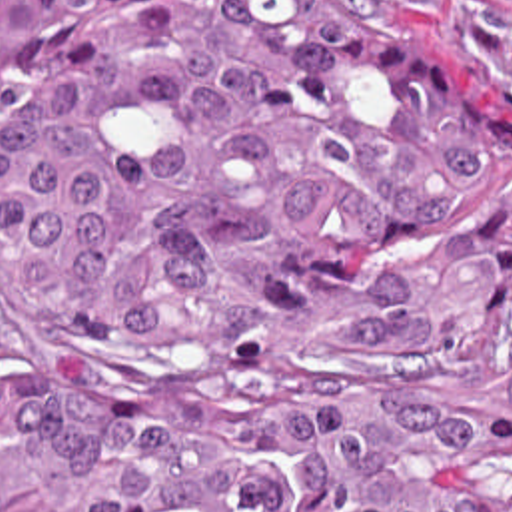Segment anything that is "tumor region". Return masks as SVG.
I'll return each mask as SVG.
<instances>
[{
	"label": "tumor region",
	"mask_w": 512,
	"mask_h": 512,
	"mask_svg": "<svg viewBox=\"0 0 512 512\" xmlns=\"http://www.w3.org/2000/svg\"><path fill=\"white\" fill-rule=\"evenodd\" d=\"M0 512H512V85L337 0H0Z\"/></svg>",
	"instance_id": "1"
}]
</instances>
